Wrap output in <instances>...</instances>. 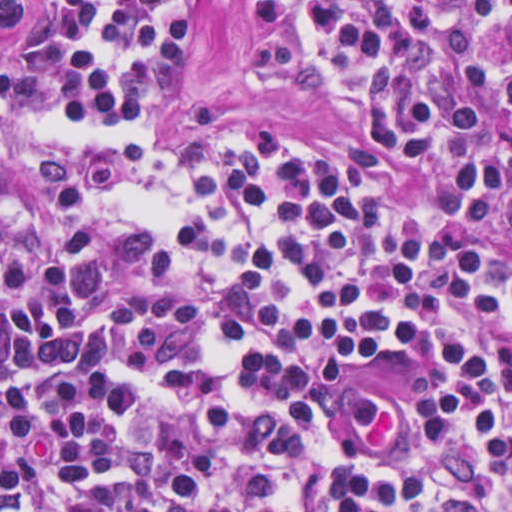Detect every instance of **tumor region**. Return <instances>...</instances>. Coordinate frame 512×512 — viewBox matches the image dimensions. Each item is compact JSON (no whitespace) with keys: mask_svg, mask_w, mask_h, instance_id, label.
Wrapping results in <instances>:
<instances>
[{"mask_svg":"<svg viewBox=\"0 0 512 512\" xmlns=\"http://www.w3.org/2000/svg\"><path fill=\"white\" fill-rule=\"evenodd\" d=\"M0 512H53L45 488L25 472L0 464Z\"/></svg>","mask_w":512,"mask_h":512,"instance_id":"e687c5a6","label":"tumor region"}]
</instances>
